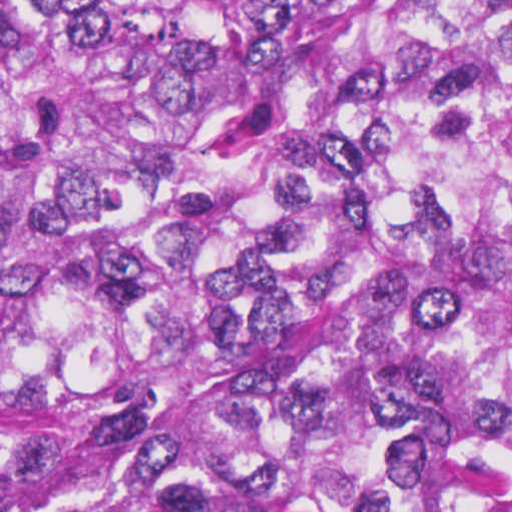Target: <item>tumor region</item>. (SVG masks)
Returning <instances> with one entry per match:
<instances>
[{
    "label": "tumor region",
    "mask_w": 512,
    "mask_h": 512,
    "mask_svg": "<svg viewBox=\"0 0 512 512\" xmlns=\"http://www.w3.org/2000/svg\"><path fill=\"white\" fill-rule=\"evenodd\" d=\"M0 512H512V0H0Z\"/></svg>",
    "instance_id": "tumor-region-1"
}]
</instances>
